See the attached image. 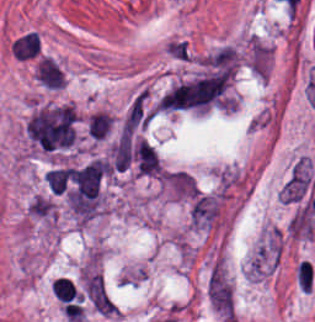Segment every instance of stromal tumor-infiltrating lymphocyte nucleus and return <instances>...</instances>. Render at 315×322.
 <instances>
[{
  "instance_id": "obj_1",
  "label": "stromal tumor-infiltrating lymphocyte nucleus",
  "mask_w": 315,
  "mask_h": 322,
  "mask_svg": "<svg viewBox=\"0 0 315 322\" xmlns=\"http://www.w3.org/2000/svg\"><path fill=\"white\" fill-rule=\"evenodd\" d=\"M35 73L40 83L52 90L62 88L66 83L64 71L53 57L41 55L37 58Z\"/></svg>"
},
{
  "instance_id": "obj_3",
  "label": "stromal tumor-infiltrating lymphocyte nucleus",
  "mask_w": 315,
  "mask_h": 322,
  "mask_svg": "<svg viewBox=\"0 0 315 322\" xmlns=\"http://www.w3.org/2000/svg\"><path fill=\"white\" fill-rule=\"evenodd\" d=\"M88 129L95 137H102L110 130V114L98 110L88 116Z\"/></svg>"
},
{
  "instance_id": "obj_2",
  "label": "stromal tumor-infiltrating lymphocyte nucleus",
  "mask_w": 315,
  "mask_h": 322,
  "mask_svg": "<svg viewBox=\"0 0 315 322\" xmlns=\"http://www.w3.org/2000/svg\"><path fill=\"white\" fill-rule=\"evenodd\" d=\"M10 48L19 60H36L40 57V40L37 34L30 31L18 37Z\"/></svg>"
}]
</instances>
